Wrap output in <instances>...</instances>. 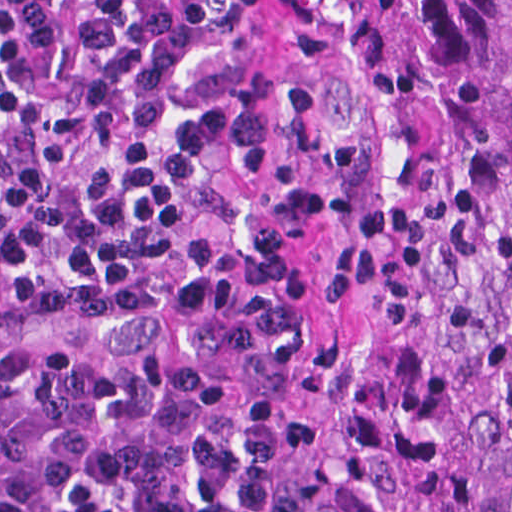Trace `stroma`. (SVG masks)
Segmentation results:
<instances>
[{
  "label": "stroma",
  "mask_w": 512,
  "mask_h": 512,
  "mask_svg": "<svg viewBox=\"0 0 512 512\" xmlns=\"http://www.w3.org/2000/svg\"><path fill=\"white\" fill-rule=\"evenodd\" d=\"M204 29L190 78L206 101L279 114L262 148L203 160L123 0H113L177 143L207 168L162 244L106 292L70 289L29 260L0 268V349L61 344L129 356L95 331L101 312L178 289H204L315 320L321 242L350 159L334 133L324 24L332 0H178ZM246 399H253L246 397ZM284 415V414H283ZM280 512H307L299 428L284 415Z\"/></svg>",
  "instance_id": "obj_1"
}]
</instances>
